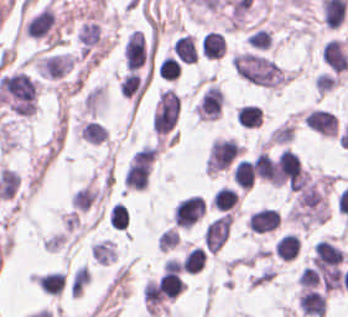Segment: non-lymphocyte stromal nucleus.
<instances>
[{"label":"non-lymphocyte stromal nucleus","instance_id":"non-lymphocyte-stromal-nucleus-2","mask_svg":"<svg viewBox=\"0 0 348 317\" xmlns=\"http://www.w3.org/2000/svg\"><path fill=\"white\" fill-rule=\"evenodd\" d=\"M179 113L178 93L162 89L152 114V129L156 134H163L173 128Z\"/></svg>","mask_w":348,"mask_h":317},{"label":"non-lymphocyte stromal nucleus","instance_id":"non-lymphocyte-stromal-nucleus-3","mask_svg":"<svg viewBox=\"0 0 348 317\" xmlns=\"http://www.w3.org/2000/svg\"><path fill=\"white\" fill-rule=\"evenodd\" d=\"M231 219V213H224L208 224L203 234L204 244L208 249L216 253L222 248L230 234Z\"/></svg>","mask_w":348,"mask_h":317},{"label":"non-lymphocyte stromal nucleus","instance_id":"non-lymphocyte-stromal-nucleus-1","mask_svg":"<svg viewBox=\"0 0 348 317\" xmlns=\"http://www.w3.org/2000/svg\"><path fill=\"white\" fill-rule=\"evenodd\" d=\"M233 68L240 77L254 84L273 88L286 82V73L271 59L261 54H235Z\"/></svg>","mask_w":348,"mask_h":317}]
</instances>
